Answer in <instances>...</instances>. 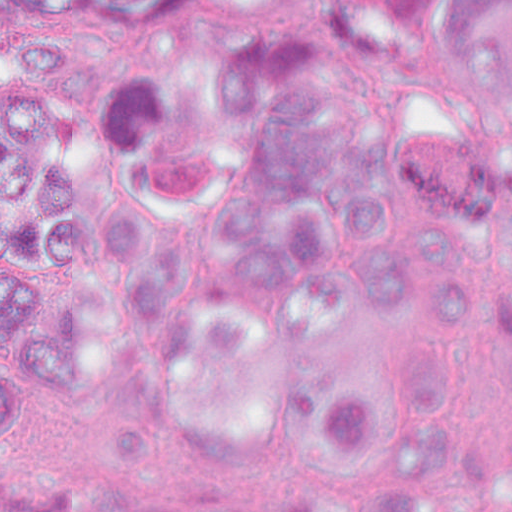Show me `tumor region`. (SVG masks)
Instances as JSON below:
<instances>
[{
  "mask_svg": "<svg viewBox=\"0 0 512 512\" xmlns=\"http://www.w3.org/2000/svg\"><path fill=\"white\" fill-rule=\"evenodd\" d=\"M0 54L19 88L0 115V331L111 351L242 339L257 277L162 217L169 195L220 173V143L136 59L84 68L47 0L5 15Z\"/></svg>",
  "mask_w": 512,
  "mask_h": 512,
  "instance_id": "e687c5a6",
  "label": "tumor region"
}]
</instances>
